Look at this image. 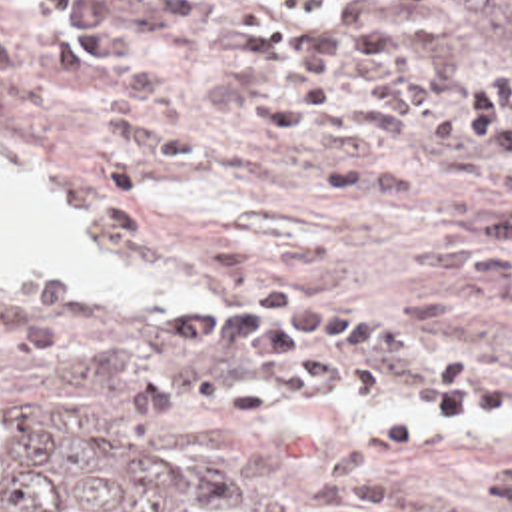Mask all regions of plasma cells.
Masks as SVG:
<instances>
[{
  "label": "plasma cells",
  "instance_id": "9512152a",
  "mask_svg": "<svg viewBox=\"0 0 512 512\" xmlns=\"http://www.w3.org/2000/svg\"><path fill=\"white\" fill-rule=\"evenodd\" d=\"M154 19L196 23L238 91L288 141L354 154L316 180L322 194L388 202L430 192L512 196V87L436 79L378 27L370 0H324L294 13L278 0L236 15L218 0H37L39 51L77 79L121 63ZM25 67L0 27V85ZM412 254L450 290L512 310V198L482 204L416 240ZM152 346L232 354L230 368L158 366L131 382L149 426L186 408L276 424L336 402L410 404L312 458L250 512H362L386 502L366 462L412 450L476 418L512 424V348L474 358L394 322L360 298H314L296 282H256L220 306L170 302L145 324ZM480 500L512 512V460L490 468Z\"/></svg>",
  "mask_w": 512,
  "mask_h": 512
}]
</instances>
